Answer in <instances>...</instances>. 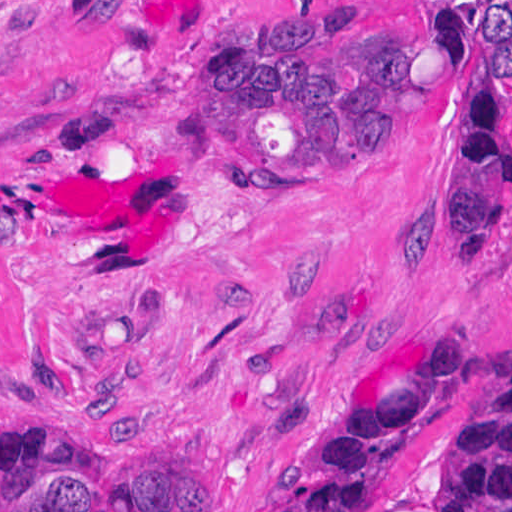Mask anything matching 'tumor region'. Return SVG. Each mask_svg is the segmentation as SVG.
Wrapping results in <instances>:
<instances>
[{
  "label": "tumor region",
  "mask_w": 512,
  "mask_h": 512,
  "mask_svg": "<svg viewBox=\"0 0 512 512\" xmlns=\"http://www.w3.org/2000/svg\"><path fill=\"white\" fill-rule=\"evenodd\" d=\"M441 1H270L211 68L207 126L223 171L245 180H325L347 170ZM472 362L444 335L423 375L326 442L278 512H369L398 450L441 410ZM27 372L66 397L33 341ZM19 394L40 397L20 369ZM79 406L119 410L98 389ZM0 512H193V480L148 455H86L0 427ZM447 512H512V368Z\"/></svg>",
  "instance_id": "tumor-region-1"
}]
</instances>
